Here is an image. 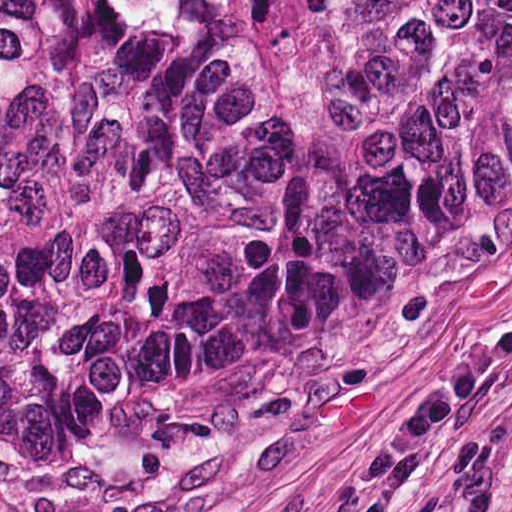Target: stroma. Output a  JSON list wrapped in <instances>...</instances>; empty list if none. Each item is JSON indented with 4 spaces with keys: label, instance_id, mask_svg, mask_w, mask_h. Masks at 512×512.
I'll return each mask as SVG.
<instances>
[{
    "label": "stroma",
    "instance_id": "obj_1",
    "mask_svg": "<svg viewBox=\"0 0 512 512\" xmlns=\"http://www.w3.org/2000/svg\"><path fill=\"white\" fill-rule=\"evenodd\" d=\"M0 512H512V141L293 338L0 457Z\"/></svg>",
    "mask_w": 512,
    "mask_h": 512
}]
</instances>
